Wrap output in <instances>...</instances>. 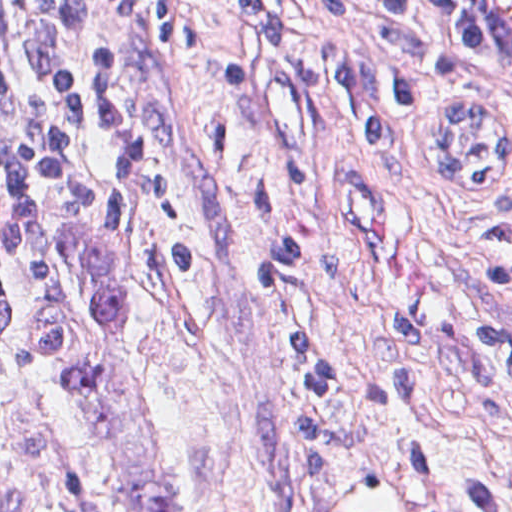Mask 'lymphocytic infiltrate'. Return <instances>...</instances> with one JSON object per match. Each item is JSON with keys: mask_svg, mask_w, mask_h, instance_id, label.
Returning <instances> with one entry per match:
<instances>
[{"mask_svg": "<svg viewBox=\"0 0 512 512\" xmlns=\"http://www.w3.org/2000/svg\"><path fill=\"white\" fill-rule=\"evenodd\" d=\"M55 0H0V346L25 280L39 225L67 198L89 191L90 171L64 146L43 94V26ZM228 23L207 63L220 87L283 90L356 107L382 134L410 111H446L451 191H485L512 162V130L498 120L464 65L461 47L424 0H84L88 55L102 133L120 184L142 194L165 220L182 217L180 196L159 152L153 63L190 51L204 14ZM310 176L298 161L257 185L262 208L286 202ZM480 249L512 255V202L479 231ZM323 272V246L287 243L251 267L258 286H287L298 267ZM159 274L199 283L192 240L171 242ZM489 283L512 291V263H495ZM322 319L290 331L305 377L288 404V425L305 512H333L342 491L344 422L320 375ZM512 347V331L489 323ZM299 438L305 500L299 477Z\"/></svg>", "mask_w": 512, "mask_h": 512, "instance_id": "1", "label": "lymphocytic infiltrate"}]
</instances>
